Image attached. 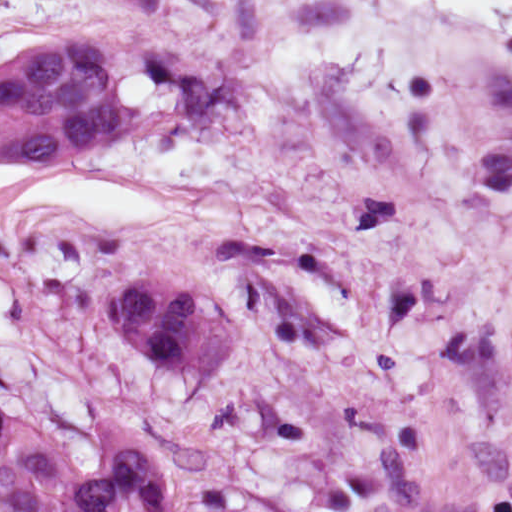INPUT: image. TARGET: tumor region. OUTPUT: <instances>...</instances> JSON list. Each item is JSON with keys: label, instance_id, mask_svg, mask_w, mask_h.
<instances>
[{"label": "tumor region", "instance_id": "tumor-region-1", "mask_svg": "<svg viewBox=\"0 0 512 512\" xmlns=\"http://www.w3.org/2000/svg\"><path fill=\"white\" fill-rule=\"evenodd\" d=\"M112 40H48L0 66V158L56 165L133 132ZM111 329L171 364L226 369L241 336L232 306L194 284L139 276L115 285ZM0 407V512H298L239 484L221 441L191 428L121 418L106 459L81 469L42 426Z\"/></svg>", "mask_w": 512, "mask_h": 512}]
</instances>
